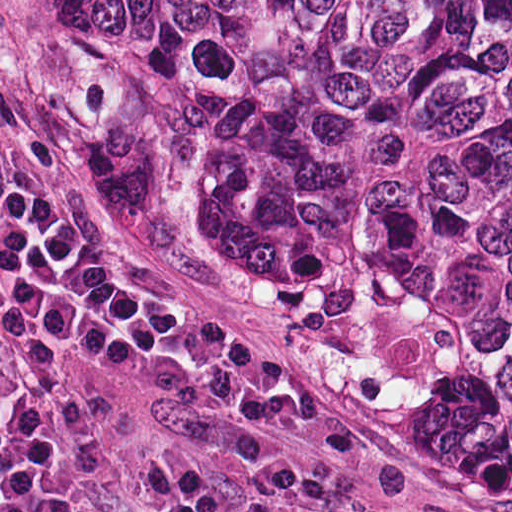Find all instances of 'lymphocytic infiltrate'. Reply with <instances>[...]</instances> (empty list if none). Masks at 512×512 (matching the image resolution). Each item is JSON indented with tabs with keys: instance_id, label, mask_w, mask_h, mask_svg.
Returning <instances> with one entry per match:
<instances>
[{
	"instance_id": "1",
	"label": "lymphocytic infiltrate",
	"mask_w": 512,
	"mask_h": 512,
	"mask_svg": "<svg viewBox=\"0 0 512 512\" xmlns=\"http://www.w3.org/2000/svg\"><path fill=\"white\" fill-rule=\"evenodd\" d=\"M85 359L184 406L299 424L296 397L256 388L235 351L196 335L168 284L70 210L0 69V512H106L59 468L77 459L48 398ZM177 512H238L201 444L167 450Z\"/></svg>"
}]
</instances>
